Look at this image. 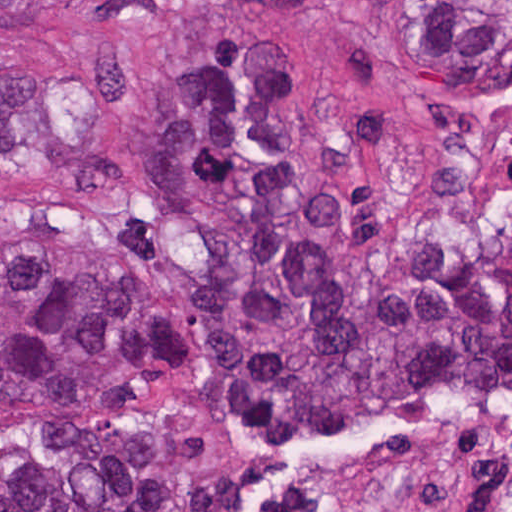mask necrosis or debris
Wrapping results in <instances>:
<instances>
[{"label": "necrosis or debris", "instance_id": "obj_1", "mask_svg": "<svg viewBox=\"0 0 512 512\" xmlns=\"http://www.w3.org/2000/svg\"><path fill=\"white\" fill-rule=\"evenodd\" d=\"M489 512H512V489L503 493Z\"/></svg>", "mask_w": 512, "mask_h": 512}]
</instances>
